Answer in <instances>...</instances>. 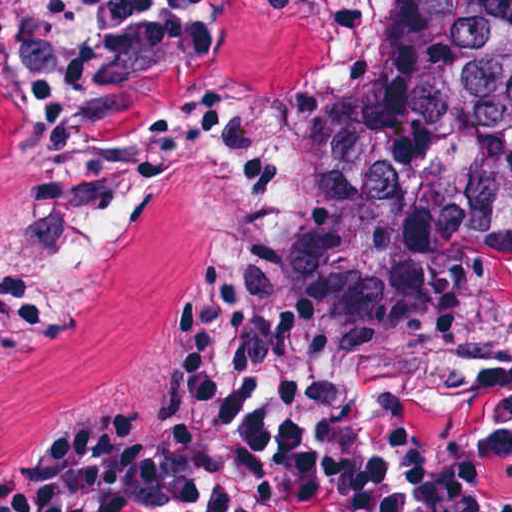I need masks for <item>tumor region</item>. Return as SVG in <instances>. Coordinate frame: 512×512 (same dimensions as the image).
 <instances>
[{"instance_id":"e687c5a6","label":"tumor region","mask_w":512,"mask_h":512,"mask_svg":"<svg viewBox=\"0 0 512 512\" xmlns=\"http://www.w3.org/2000/svg\"><path fill=\"white\" fill-rule=\"evenodd\" d=\"M238 114L274 134L268 189L165 173L85 234L51 220L35 131L0 102V287L45 293L36 310L0 303V452L68 442L163 357L210 276L265 280L324 373L357 389L315 280L348 182L370 339L486 350L512 334V0H219L214 52L140 68L108 147ZM380 416L400 454L486 463V427Z\"/></svg>"}]
</instances>
